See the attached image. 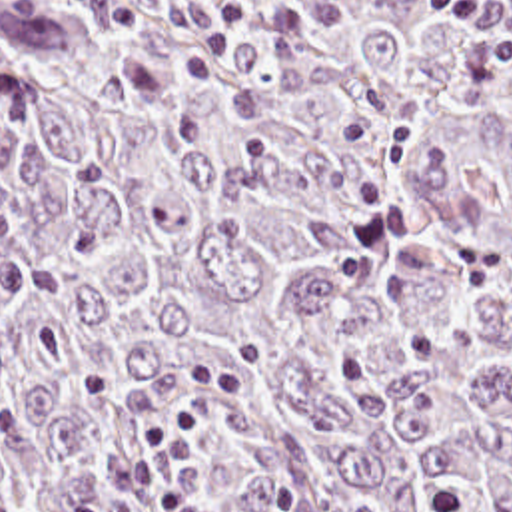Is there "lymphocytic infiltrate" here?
I'll use <instances>...</instances> for the list:
<instances>
[{
  "mask_svg": "<svg viewBox=\"0 0 512 512\" xmlns=\"http://www.w3.org/2000/svg\"><path fill=\"white\" fill-rule=\"evenodd\" d=\"M431 11L449 23L473 25L487 55L512 75V0H431ZM26 291V245L14 217L0 201V295ZM247 391L243 381L213 365L189 367L181 399L142 433V449L155 473L145 512L195 508L191 439L203 423V407L219 395Z\"/></svg>",
  "mask_w": 512,
  "mask_h": 512,
  "instance_id": "obj_1",
  "label": "lymphocytic infiltrate"
}]
</instances>
